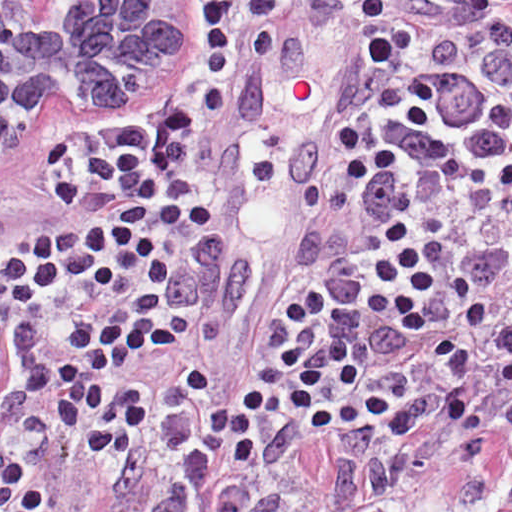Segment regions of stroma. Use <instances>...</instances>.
<instances>
[{"mask_svg": "<svg viewBox=\"0 0 512 512\" xmlns=\"http://www.w3.org/2000/svg\"><path fill=\"white\" fill-rule=\"evenodd\" d=\"M0 1H185L160 54L154 88L134 110L95 127H49L0 154V244L22 251L52 233L57 207L77 190L86 164L130 139L155 154L173 201V241L144 280L93 307H62L13 379V454L58 512H357L381 502L395 512H512V470L456 464L435 441L459 429L432 423L390 446L371 420L314 433L272 416L259 427L252 465H235L225 451L201 445L202 423L223 396L251 380L289 381L277 356L287 325L281 310L291 299L306 308L300 330L306 355L317 357L329 336L343 339L357 353L361 374L399 404L441 387L444 370L432 339L465 347L477 369L490 363L496 333L512 326V279L492 293L487 323L473 336L448 271L474 248L512 245L506 209L489 195L446 188L403 153L401 139L462 150L443 135L399 125L382 115L377 100L382 88L413 77L432 35L452 39L472 75L500 95L512 75V0ZM399 1L408 3L397 14ZM291 18L329 40V69L336 38L359 98L371 83L369 95L303 269L244 318L215 372L200 274L193 260L181 259L250 51L269 24ZM409 170L411 180L403 177ZM391 221L411 231L419 252L442 249L438 292L423 302L431 323L424 336L365 306L378 291L370 263ZM140 290L156 293V318L172 328L174 344L143 352L106 377L108 393L140 390L146 422L127 453L95 456L53 421L47 398L24 392L21 374L62 358L59 332L66 322L103 315ZM466 390L487 415L512 404V387L493 381Z\"/></svg>", "mask_w": 512, "mask_h": 512, "instance_id": "35a3bbf8", "label": "stroma"}]
</instances>
